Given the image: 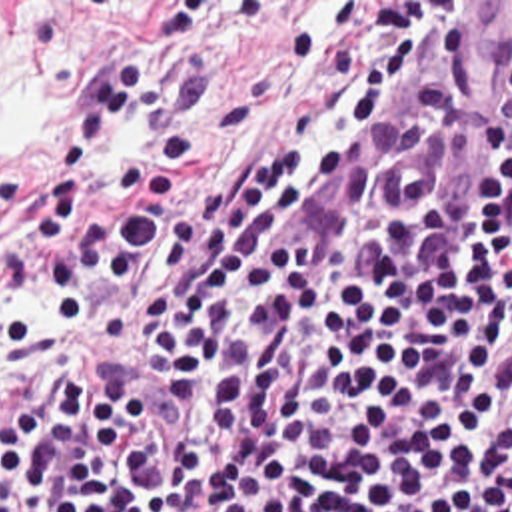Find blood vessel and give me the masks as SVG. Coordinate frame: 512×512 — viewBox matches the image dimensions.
Segmentation results:
<instances>
[{"mask_svg":"<svg viewBox=\"0 0 512 512\" xmlns=\"http://www.w3.org/2000/svg\"><path fill=\"white\" fill-rule=\"evenodd\" d=\"M510 112L512 2H460L418 82L312 202L302 228L324 244H352L372 198L410 212L436 194L424 230L472 238Z\"/></svg>","mask_w":512,"mask_h":512,"instance_id":"8fb6f2fc","label":"blood vessel"}]
</instances>
